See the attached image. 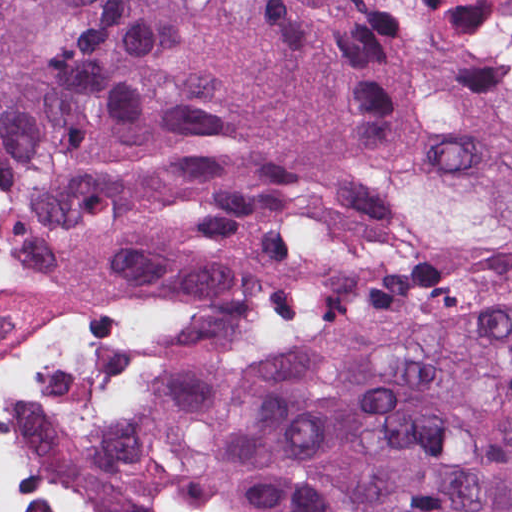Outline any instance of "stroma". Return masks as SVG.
<instances>
[{
    "instance_id": "35a3bbf8",
    "label": "stroma",
    "mask_w": 512,
    "mask_h": 512,
    "mask_svg": "<svg viewBox=\"0 0 512 512\" xmlns=\"http://www.w3.org/2000/svg\"><path fill=\"white\" fill-rule=\"evenodd\" d=\"M6 294L40 352L88 414V512H122L99 435L98 400L51 337L7 292Z\"/></svg>"
}]
</instances>
